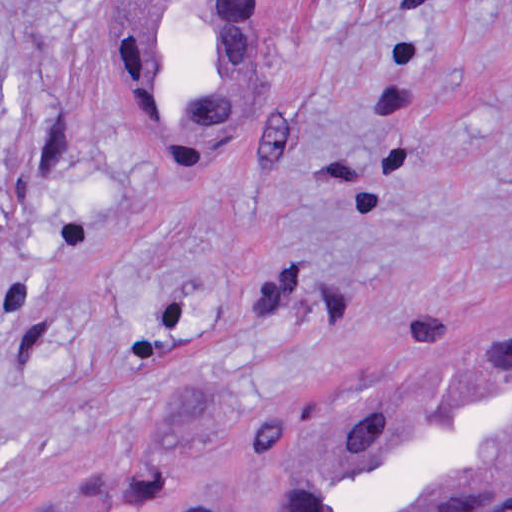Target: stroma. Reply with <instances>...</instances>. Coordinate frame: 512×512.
I'll return each mask as SVG.
<instances>
[{
  "mask_svg": "<svg viewBox=\"0 0 512 512\" xmlns=\"http://www.w3.org/2000/svg\"><path fill=\"white\" fill-rule=\"evenodd\" d=\"M142 1H278L210 177L136 137ZM0 60V512L82 471L266 512L283 455L512 339V0H0Z\"/></svg>",
  "mask_w": 512,
  "mask_h": 512,
  "instance_id": "1",
  "label": "stroma"
}]
</instances>
